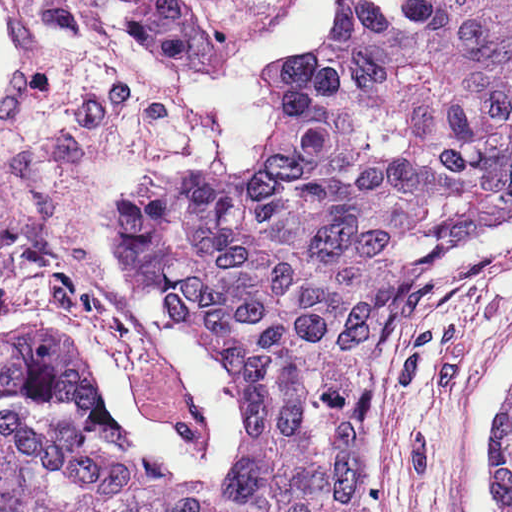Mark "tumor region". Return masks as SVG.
I'll use <instances>...</instances> for the list:
<instances>
[{
    "instance_id": "tumor-region-1",
    "label": "tumor region",
    "mask_w": 512,
    "mask_h": 512,
    "mask_svg": "<svg viewBox=\"0 0 512 512\" xmlns=\"http://www.w3.org/2000/svg\"><path fill=\"white\" fill-rule=\"evenodd\" d=\"M0 512H31L0 445Z\"/></svg>"
}]
</instances>
